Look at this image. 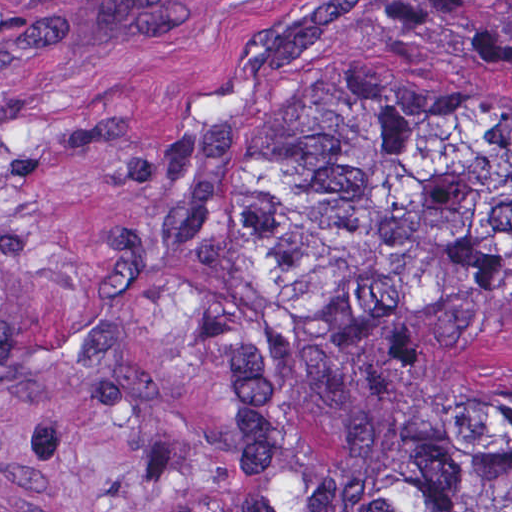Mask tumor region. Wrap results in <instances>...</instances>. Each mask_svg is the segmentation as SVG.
<instances>
[{"instance_id":"e687c5a6","label":"tumor region","mask_w":512,"mask_h":512,"mask_svg":"<svg viewBox=\"0 0 512 512\" xmlns=\"http://www.w3.org/2000/svg\"><path fill=\"white\" fill-rule=\"evenodd\" d=\"M205 512H512V29L344 78L224 283Z\"/></svg>"}]
</instances>
